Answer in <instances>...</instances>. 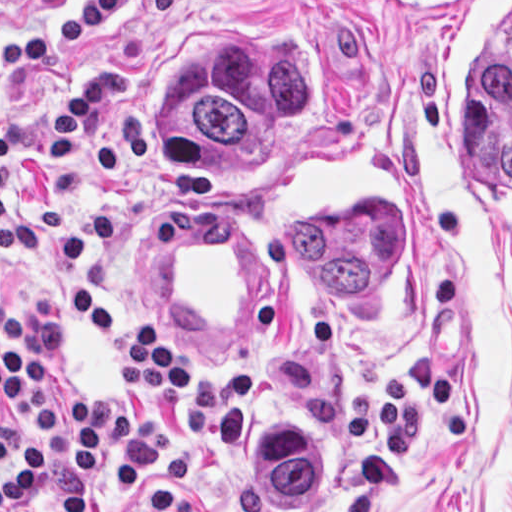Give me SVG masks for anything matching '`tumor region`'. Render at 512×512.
<instances>
[{"label": "tumor region", "instance_id": "obj_1", "mask_svg": "<svg viewBox=\"0 0 512 512\" xmlns=\"http://www.w3.org/2000/svg\"><path fill=\"white\" fill-rule=\"evenodd\" d=\"M318 96V52L240 40L169 63L152 86V121L166 170H228L258 153ZM290 210L286 231L305 267L347 296L377 287L403 255L401 210ZM218 457L237 494L316 500L338 475L334 439L316 414H240Z\"/></svg>", "mask_w": 512, "mask_h": 512}]
</instances>
